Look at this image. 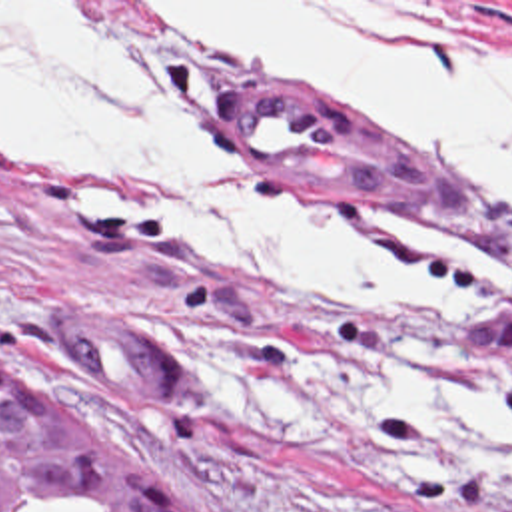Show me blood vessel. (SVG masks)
<instances>
[{
	"label": "blood vessel",
	"mask_w": 512,
	"mask_h": 512,
	"mask_svg": "<svg viewBox=\"0 0 512 512\" xmlns=\"http://www.w3.org/2000/svg\"><path fill=\"white\" fill-rule=\"evenodd\" d=\"M225 110L231 142L245 162L347 178L418 204L498 220V202L488 190L452 178L293 84L233 82ZM47 337L77 387L153 407H183L189 399L187 365L99 303L63 301Z\"/></svg>",
	"instance_id": "1"
}]
</instances>
